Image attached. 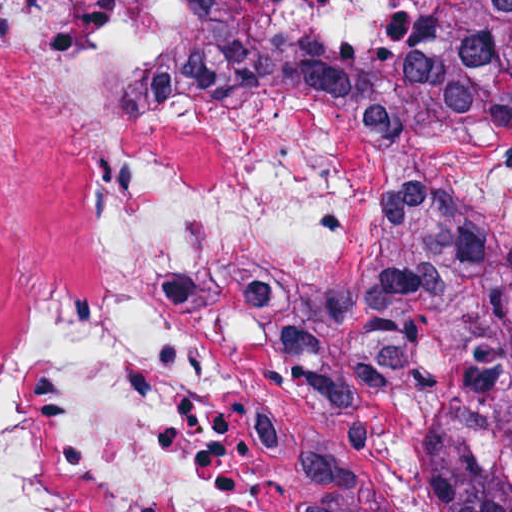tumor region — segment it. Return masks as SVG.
Listing matches in <instances>:
<instances>
[{
    "instance_id": "tumor-region-1",
    "label": "tumor region",
    "mask_w": 512,
    "mask_h": 512,
    "mask_svg": "<svg viewBox=\"0 0 512 512\" xmlns=\"http://www.w3.org/2000/svg\"><path fill=\"white\" fill-rule=\"evenodd\" d=\"M420 1L427 35L364 42L192 0L191 39L139 90L296 97L379 137L512 126V0ZM336 380L380 460L370 512H512V219L449 191L400 198L359 265Z\"/></svg>"
}]
</instances>
